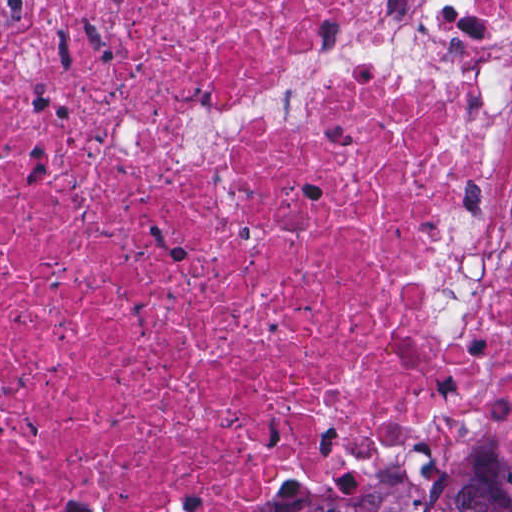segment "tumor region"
<instances>
[{"label": "tumor region", "instance_id": "e687c5a6", "mask_svg": "<svg viewBox=\"0 0 512 512\" xmlns=\"http://www.w3.org/2000/svg\"><path fill=\"white\" fill-rule=\"evenodd\" d=\"M271 512H512V443L448 440L365 478L309 488Z\"/></svg>", "mask_w": 512, "mask_h": 512}]
</instances>
